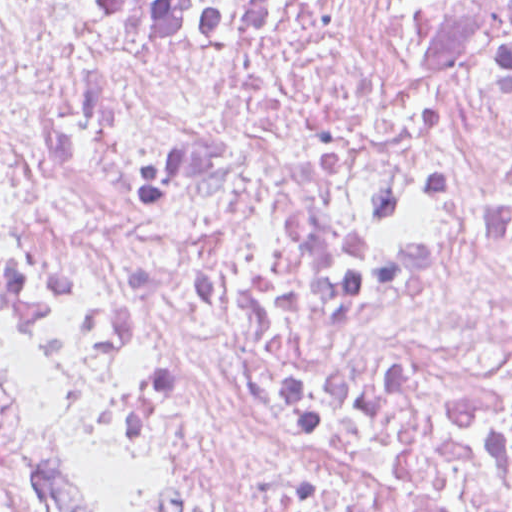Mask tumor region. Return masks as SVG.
<instances>
[{
	"instance_id": "e687c5a6",
	"label": "tumor region",
	"mask_w": 512,
	"mask_h": 512,
	"mask_svg": "<svg viewBox=\"0 0 512 512\" xmlns=\"http://www.w3.org/2000/svg\"><path fill=\"white\" fill-rule=\"evenodd\" d=\"M0 512H69L29 435L22 395L0 354Z\"/></svg>"
}]
</instances>
